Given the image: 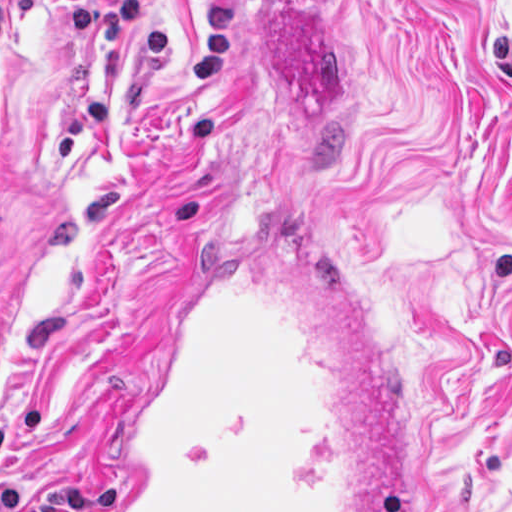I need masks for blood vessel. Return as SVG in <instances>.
<instances>
[{
    "label": "blood vessel",
    "instance_id": "obj_1",
    "mask_svg": "<svg viewBox=\"0 0 512 512\" xmlns=\"http://www.w3.org/2000/svg\"><path fill=\"white\" fill-rule=\"evenodd\" d=\"M217 211L151 330L107 512H413L299 186Z\"/></svg>",
    "mask_w": 512,
    "mask_h": 512
}]
</instances>
